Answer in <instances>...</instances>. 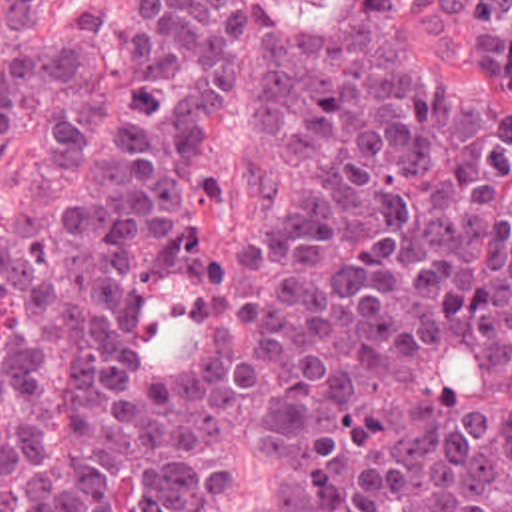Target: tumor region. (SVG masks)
Here are the masks:
<instances>
[{
	"mask_svg": "<svg viewBox=\"0 0 512 512\" xmlns=\"http://www.w3.org/2000/svg\"><path fill=\"white\" fill-rule=\"evenodd\" d=\"M0 0V512H512V111L422 77L434 0H264L244 205L202 257L238 0ZM512 87V0H442Z\"/></svg>",
	"mask_w": 512,
	"mask_h": 512,
	"instance_id": "tumor-region-1",
	"label": "tumor region"
}]
</instances>
